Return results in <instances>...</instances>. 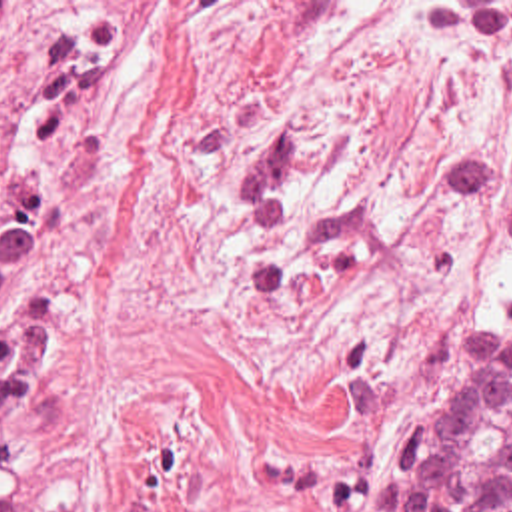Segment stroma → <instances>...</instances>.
Returning a JSON list of instances; mask_svg holds the SVG:
<instances>
[{"label": "stroma", "mask_w": 512, "mask_h": 512, "mask_svg": "<svg viewBox=\"0 0 512 512\" xmlns=\"http://www.w3.org/2000/svg\"><path fill=\"white\" fill-rule=\"evenodd\" d=\"M43 150L19 472L83 512H373L512 304V0H87Z\"/></svg>", "instance_id": "stroma-1"}]
</instances>
